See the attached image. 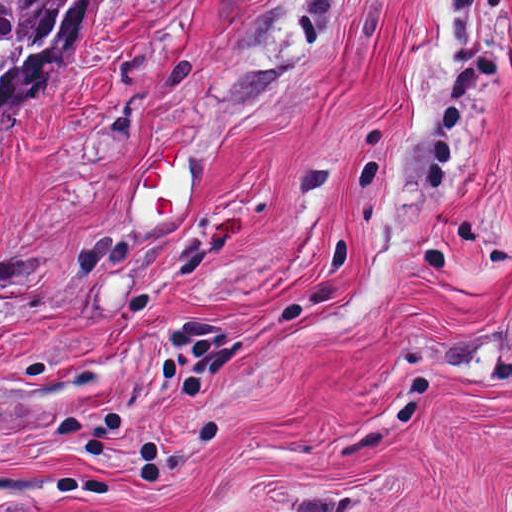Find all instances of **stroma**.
I'll return each instance as SVG.
<instances>
[{
  "label": "stroma",
  "instance_id": "obj_1",
  "mask_svg": "<svg viewBox=\"0 0 512 512\" xmlns=\"http://www.w3.org/2000/svg\"><path fill=\"white\" fill-rule=\"evenodd\" d=\"M0 376V512H512V0H104L0 115Z\"/></svg>",
  "mask_w": 512,
  "mask_h": 512
}]
</instances>
